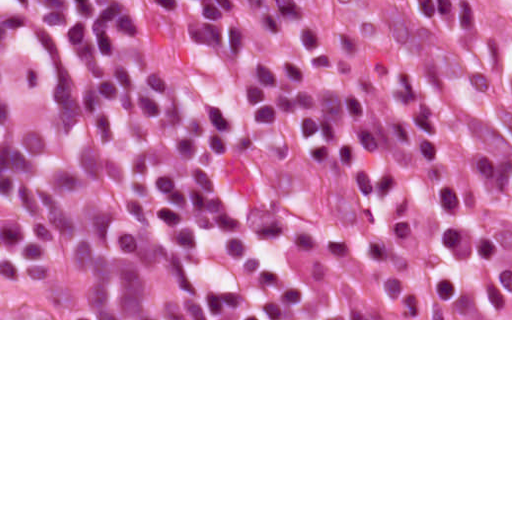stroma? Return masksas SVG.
I'll use <instances>...</instances> for the list:
<instances>
[{"label":"stroma","mask_w":512,"mask_h":512,"mask_svg":"<svg viewBox=\"0 0 512 512\" xmlns=\"http://www.w3.org/2000/svg\"><path fill=\"white\" fill-rule=\"evenodd\" d=\"M322 23L378 30L408 0H297ZM455 48L448 55L450 91L466 128L512 159V0H453ZM466 189V155H465ZM177 278L214 283L210 318H0V320H512V303L441 310H398L299 303L166 251ZM380 261V260H304Z\"/></svg>","instance_id":"stroma-1"}]
</instances>
